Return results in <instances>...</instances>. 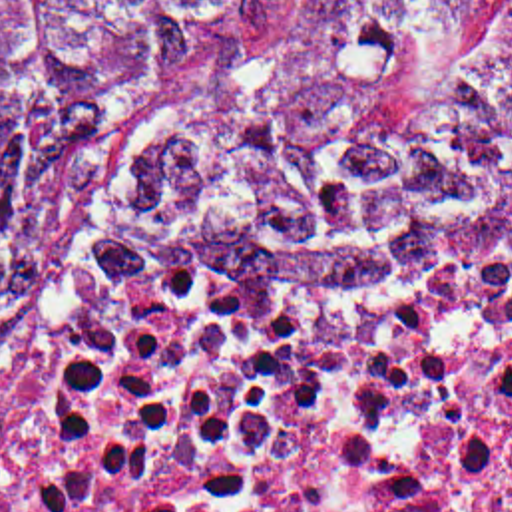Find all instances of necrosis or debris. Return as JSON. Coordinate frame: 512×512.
<instances>
[{
  "instance_id": "4bbe7bcc",
  "label": "necrosis or debris",
  "mask_w": 512,
  "mask_h": 512,
  "mask_svg": "<svg viewBox=\"0 0 512 512\" xmlns=\"http://www.w3.org/2000/svg\"><path fill=\"white\" fill-rule=\"evenodd\" d=\"M0 512H512V273L223 291L105 215L0 400Z\"/></svg>"
}]
</instances>
